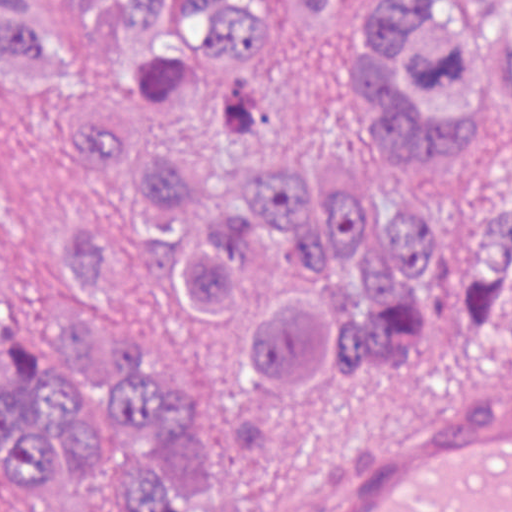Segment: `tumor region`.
<instances>
[{
    "instance_id": "1",
    "label": "tumor region",
    "mask_w": 512,
    "mask_h": 512,
    "mask_svg": "<svg viewBox=\"0 0 512 512\" xmlns=\"http://www.w3.org/2000/svg\"><path fill=\"white\" fill-rule=\"evenodd\" d=\"M90 75L31 0H0V79L59 103L102 206L61 220L79 315L18 307L0 225V512H224L212 446L152 351L156 298L207 364L282 402L512 310V202L429 206L314 154L255 89L301 30L373 165L468 173L512 130V0H66ZM20 315L47 332H32Z\"/></svg>"
}]
</instances>
